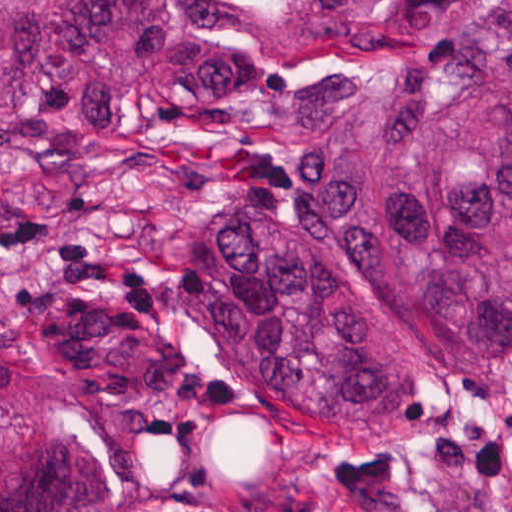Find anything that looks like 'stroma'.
I'll list each match as a JSON object with an SVG mask.
<instances>
[{"label": "stroma", "mask_w": 512, "mask_h": 512, "mask_svg": "<svg viewBox=\"0 0 512 512\" xmlns=\"http://www.w3.org/2000/svg\"><path fill=\"white\" fill-rule=\"evenodd\" d=\"M242 41L267 81H301L265 53L272 0ZM94 160L55 171L0 154V226L40 217L144 273L147 338L115 327L116 295L64 277L40 242L0 248V423L20 410L80 420L104 467V512H512V365L457 377L422 435L357 450L275 412L210 358L170 296L179 218L200 204L286 202L287 135L239 131L184 98L148 99ZM118 269H129L120 267Z\"/></svg>", "instance_id": "1"}]
</instances>
